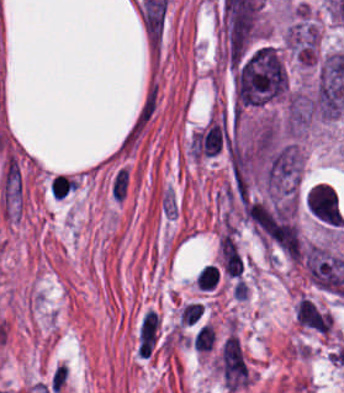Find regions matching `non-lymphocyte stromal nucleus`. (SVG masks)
<instances>
[{
    "label": "non-lymphocyte stromal nucleus",
    "instance_id": "obj_4",
    "mask_svg": "<svg viewBox=\"0 0 344 393\" xmlns=\"http://www.w3.org/2000/svg\"><path fill=\"white\" fill-rule=\"evenodd\" d=\"M182 206L176 189L166 186L162 189L160 198V212L166 220H175Z\"/></svg>",
    "mask_w": 344,
    "mask_h": 393
},
{
    "label": "non-lymphocyte stromal nucleus",
    "instance_id": "obj_3",
    "mask_svg": "<svg viewBox=\"0 0 344 393\" xmlns=\"http://www.w3.org/2000/svg\"><path fill=\"white\" fill-rule=\"evenodd\" d=\"M131 182V172L126 165H119L109 177V193L115 202L126 199Z\"/></svg>",
    "mask_w": 344,
    "mask_h": 393
},
{
    "label": "non-lymphocyte stromal nucleus",
    "instance_id": "obj_1",
    "mask_svg": "<svg viewBox=\"0 0 344 393\" xmlns=\"http://www.w3.org/2000/svg\"><path fill=\"white\" fill-rule=\"evenodd\" d=\"M220 372L227 388L232 393L245 387L250 379L241 340L234 333L226 338L221 348Z\"/></svg>",
    "mask_w": 344,
    "mask_h": 393
},
{
    "label": "non-lymphocyte stromal nucleus",
    "instance_id": "obj_2",
    "mask_svg": "<svg viewBox=\"0 0 344 393\" xmlns=\"http://www.w3.org/2000/svg\"><path fill=\"white\" fill-rule=\"evenodd\" d=\"M1 200L5 209L13 216L23 200V183L20 164L8 154L1 179Z\"/></svg>",
    "mask_w": 344,
    "mask_h": 393
}]
</instances>
